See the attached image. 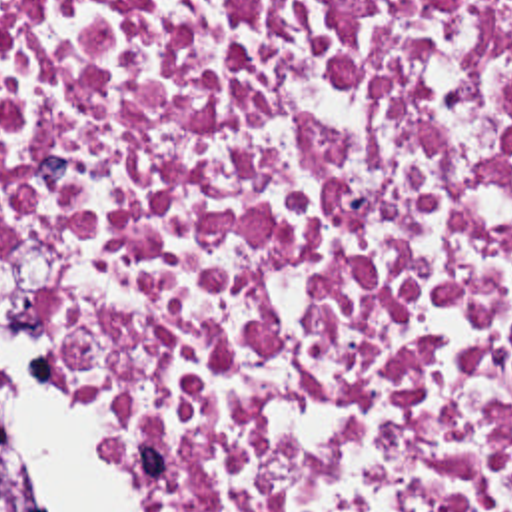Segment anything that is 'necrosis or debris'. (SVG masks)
<instances>
[{
  "mask_svg": "<svg viewBox=\"0 0 512 512\" xmlns=\"http://www.w3.org/2000/svg\"><path fill=\"white\" fill-rule=\"evenodd\" d=\"M158 512H512V0H0V227Z\"/></svg>",
  "mask_w": 512,
  "mask_h": 512,
  "instance_id": "obj_1",
  "label": "necrosis or debris"
}]
</instances>
